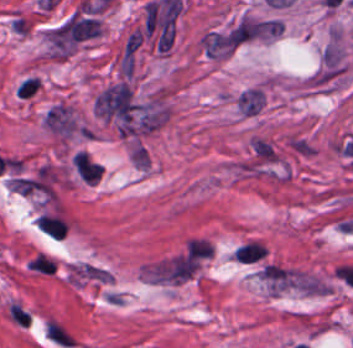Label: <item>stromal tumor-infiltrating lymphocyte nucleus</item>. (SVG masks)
I'll return each mask as SVG.
<instances>
[{"label":"stromal tumor-infiltrating lymphocyte nucleus","instance_id":"stromal-tumor-infiltrating-lymphocyte-nucleus-1","mask_svg":"<svg viewBox=\"0 0 353 348\" xmlns=\"http://www.w3.org/2000/svg\"><path fill=\"white\" fill-rule=\"evenodd\" d=\"M74 165L85 182H96L102 174L103 165L85 152H78L74 157Z\"/></svg>","mask_w":353,"mask_h":348},{"label":"stromal tumor-infiltrating lymphocyte nucleus","instance_id":"stromal-tumor-infiltrating-lymphocyte-nucleus-2","mask_svg":"<svg viewBox=\"0 0 353 348\" xmlns=\"http://www.w3.org/2000/svg\"><path fill=\"white\" fill-rule=\"evenodd\" d=\"M233 256L240 263H253L265 256V252L260 243L248 242L237 247Z\"/></svg>","mask_w":353,"mask_h":348}]
</instances>
